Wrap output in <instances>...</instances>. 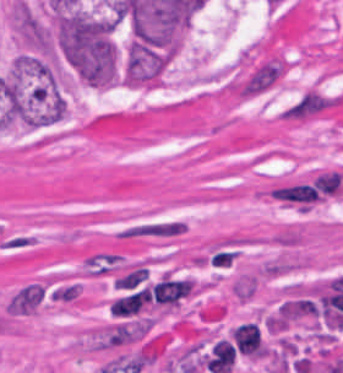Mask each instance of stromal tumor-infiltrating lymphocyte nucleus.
Returning a JSON list of instances; mask_svg holds the SVG:
<instances>
[{"label":"stromal tumor-infiltrating lymphocyte nucleus","instance_id":"bc302bb0","mask_svg":"<svg viewBox=\"0 0 343 373\" xmlns=\"http://www.w3.org/2000/svg\"><path fill=\"white\" fill-rule=\"evenodd\" d=\"M232 342L237 351L251 358H260L263 343L258 324L243 322L230 329Z\"/></svg>","mask_w":343,"mask_h":373}]
</instances>
